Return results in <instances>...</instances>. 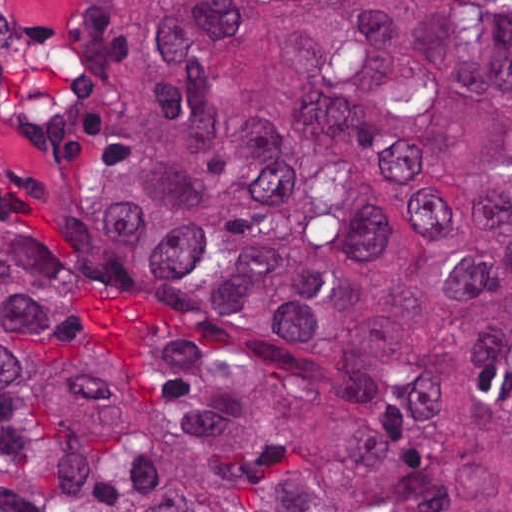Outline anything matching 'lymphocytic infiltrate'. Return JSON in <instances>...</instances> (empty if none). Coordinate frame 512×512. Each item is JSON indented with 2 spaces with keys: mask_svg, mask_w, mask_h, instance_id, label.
Instances as JSON below:
<instances>
[{
  "mask_svg": "<svg viewBox=\"0 0 512 512\" xmlns=\"http://www.w3.org/2000/svg\"><path fill=\"white\" fill-rule=\"evenodd\" d=\"M28 202V191L18 176L0 164V206H21Z\"/></svg>",
  "mask_w": 512,
  "mask_h": 512,
  "instance_id": "f902f5d3",
  "label": "lymphocytic infiltrate"
}]
</instances>
